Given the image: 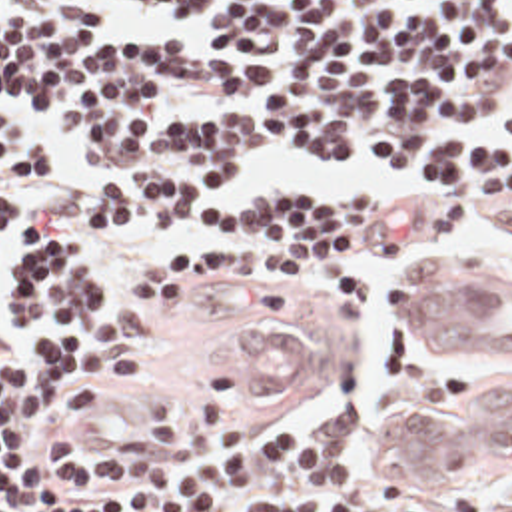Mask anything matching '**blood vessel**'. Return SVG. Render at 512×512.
<instances>
[{
    "instance_id": "1",
    "label": "blood vessel",
    "mask_w": 512,
    "mask_h": 512,
    "mask_svg": "<svg viewBox=\"0 0 512 512\" xmlns=\"http://www.w3.org/2000/svg\"><path fill=\"white\" fill-rule=\"evenodd\" d=\"M498 266L430 258L418 272L412 318L436 356H512V298ZM227 364L267 396H301L315 380V338L283 308L247 306L229 330ZM363 448L398 476L476 478L512 466V364L462 408L376 418Z\"/></svg>"
}]
</instances>
